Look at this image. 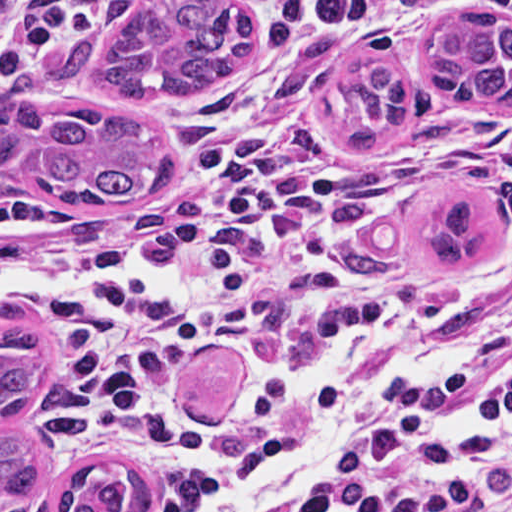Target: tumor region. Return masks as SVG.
Returning <instances> with one entry per match:
<instances>
[{
  "instance_id": "tumor-region-1",
  "label": "tumor region",
  "mask_w": 512,
  "mask_h": 512,
  "mask_svg": "<svg viewBox=\"0 0 512 512\" xmlns=\"http://www.w3.org/2000/svg\"><path fill=\"white\" fill-rule=\"evenodd\" d=\"M254 34L247 0H101L90 29L67 37L46 75L115 102H182L220 81ZM431 90L453 106H512V26L485 6L451 7L434 21L423 60ZM358 111L351 143H386L407 123L412 94L394 63L376 60L344 80ZM35 82L0 84V177L25 176L89 207L155 199L173 182L163 137L149 123L93 108L40 102ZM492 249V227L472 194L435 213L433 267L462 269ZM45 339L22 309L0 302V512L46 500L51 512H150L151 474L119 457L55 469L32 435Z\"/></svg>"
}]
</instances>
